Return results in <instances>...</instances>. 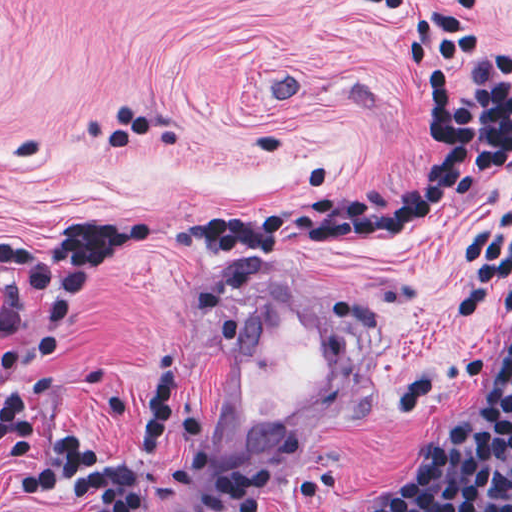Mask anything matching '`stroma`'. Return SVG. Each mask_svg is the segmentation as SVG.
Instances as JSON below:
<instances>
[{
  "instance_id": "1",
  "label": "stroma",
  "mask_w": 512,
  "mask_h": 512,
  "mask_svg": "<svg viewBox=\"0 0 512 512\" xmlns=\"http://www.w3.org/2000/svg\"><path fill=\"white\" fill-rule=\"evenodd\" d=\"M363 1H479L468 88L512 51V0H0V239L57 247L76 211L208 215L257 207L325 171L343 195L413 185L435 157L396 28ZM136 107L147 131L114 154L108 133ZM512 261V171L387 237L225 260L119 253L61 340L25 364L39 431L96 443L131 431L152 355L176 358L169 432L200 420L223 336L244 297L284 269L329 299L369 352L362 396L269 470L261 512H384L423 439L476 411L512 335L502 276ZM37 334L32 306L5 358ZM228 465L207 449L195 472ZM0 512H84L22 501L0 453ZM153 512H177L163 506Z\"/></svg>"
}]
</instances>
